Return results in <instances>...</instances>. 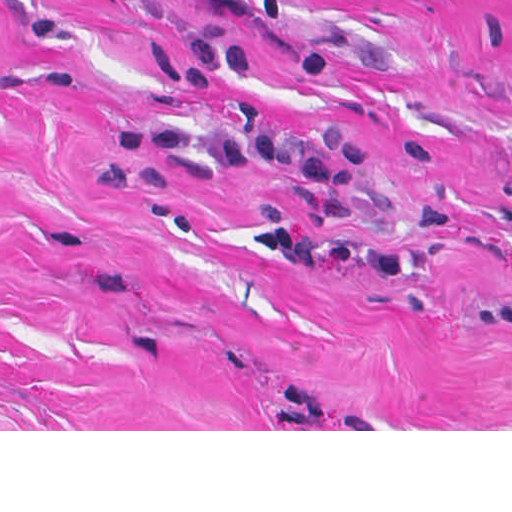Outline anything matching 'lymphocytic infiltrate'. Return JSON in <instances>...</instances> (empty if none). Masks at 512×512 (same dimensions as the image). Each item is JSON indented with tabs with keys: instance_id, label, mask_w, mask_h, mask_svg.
Listing matches in <instances>:
<instances>
[{
	"instance_id": "lymphocytic-infiltrate-1",
	"label": "lymphocytic infiltrate",
	"mask_w": 512,
	"mask_h": 512,
	"mask_svg": "<svg viewBox=\"0 0 512 512\" xmlns=\"http://www.w3.org/2000/svg\"><path fill=\"white\" fill-rule=\"evenodd\" d=\"M114 141L143 155H170L204 166L246 168L258 162L290 173L307 186L311 216L285 228L251 235L247 248L279 270L332 277H398L422 271L450 250L448 213L428 209L403 245L359 243L366 221V180L375 162L372 144L338 124L312 133L282 130L256 112L236 116L234 133L191 127L117 129Z\"/></svg>"
}]
</instances>
